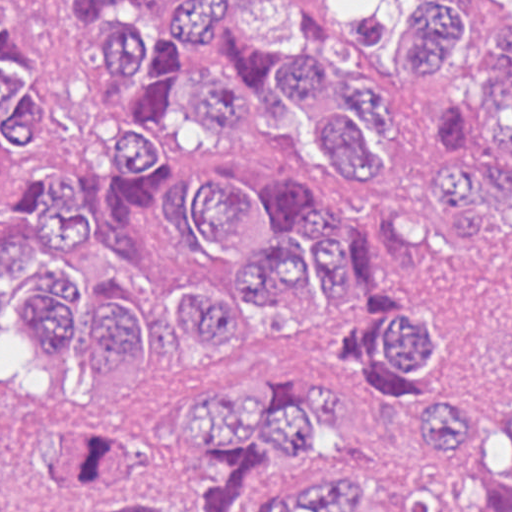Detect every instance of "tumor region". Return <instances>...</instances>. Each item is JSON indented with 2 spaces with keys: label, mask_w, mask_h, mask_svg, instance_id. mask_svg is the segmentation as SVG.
<instances>
[{
  "label": "tumor region",
  "mask_w": 512,
  "mask_h": 512,
  "mask_svg": "<svg viewBox=\"0 0 512 512\" xmlns=\"http://www.w3.org/2000/svg\"><path fill=\"white\" fill-rule=\"evenodd\" d=\"M80 44L136 95L115 133L117 167L103 211L85 207L75 179L30 191L14 171L40 135L45 100L34 61L14 35L20 0H1V324L30 326L36 349L75 347L85 377H121L147 319L176 317L207 357L294 316L313 314L361 284L377 317L368 360L390 381H414L436 360L429 317L399 296L393 223L432 201L456 214L464 247L488 229V201L512 205V21L485 45L481 93L437 105L432 134L445 151L418 203L362 228L332 223L304 184L276 179L247 191L225 168L195 162L172 182V220L192 268L218 289L161 286L134 251L129 213L167 172L158 140L176 103L182 53L228 41L189 87L210 131L256 121L266 87L291 98L322 136L342 179L381 172L363 132L390 129L387 98L332 76L312 22L322 0H162L148 32L108 20L104 0H55ZM399 22L396 38L395 29ZM468 27L456 0H366L346 20L357 54L393 46L398 74L433 79L457 59ZM347 423L344 388L244 377L222 388L162 398V452L130 459L123 433L94 415L46 422L43 471L78 512H512V404L430 394L412 412V451L427 470L407 488L334 465L324 444Z\"/></svg>",
  "instance_id": "1"
}]
</instances>
